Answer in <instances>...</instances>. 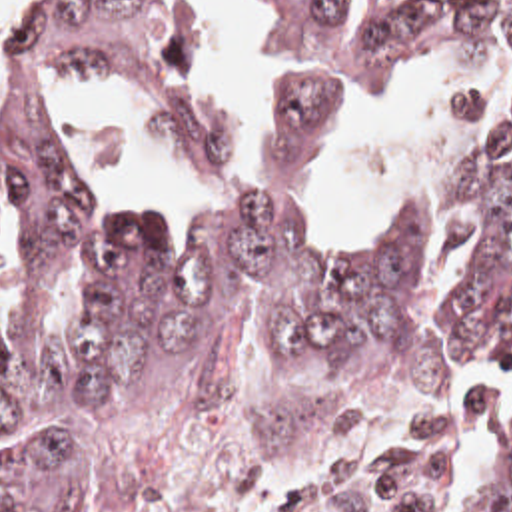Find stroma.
Instances as JSON below:
<instances>
[{
	"mask_svg": "<svg viewBox=\"0 0 512 512\" xmlns=\"http://www.w3.org/2000/svg\"><path fill=\"white\" fill-rule=\"evenodd\" d=\"M14 378V430L0 462L18 452L60 458L108 512H469L361 489L345 462L291 477H152L100 454Z\"/></svg>",
	"mask_w": 512,
	"mask_h": 512,
	"instance_id": "1",
	"label": "stroma"
}]
</instances>
